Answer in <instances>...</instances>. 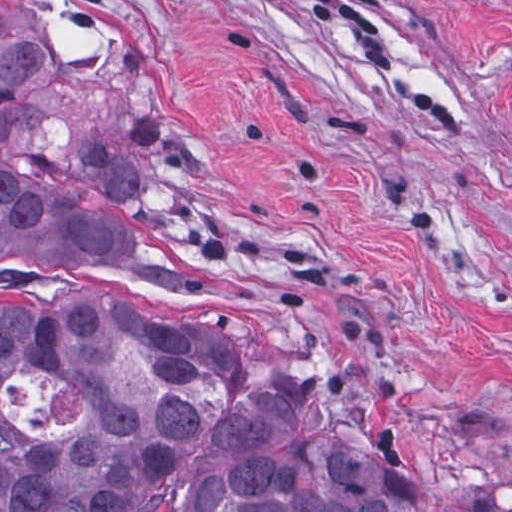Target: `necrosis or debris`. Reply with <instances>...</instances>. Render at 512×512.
<instances>
[{"label": "necrosis or debris", "instance_id": "obj_1", "mask_svg": "<svg viewBox=\"0 0 512 512\" xmlns=\"http://www.w3.org/2000/svg\"><path fill=\"white\" fill-rule=\"evenodd\" d=\"M0 410L23 433H59L80 416V394L35 372L11 370L0 385Z\"/></svg>", "mask_w": 512, "mask_h": 512}]
</instances>
